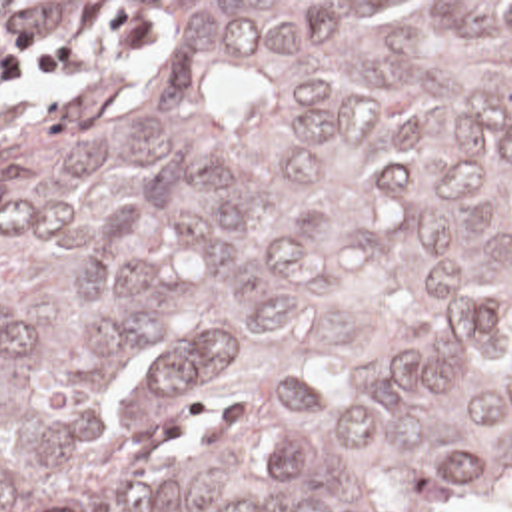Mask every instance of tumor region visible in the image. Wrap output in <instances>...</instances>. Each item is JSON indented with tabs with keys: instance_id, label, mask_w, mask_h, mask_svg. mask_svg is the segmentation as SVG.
<instances>
[{
	"instance_id": "tumor-region-1",
	"label": "tumor region",
	"mask_w": 512,
	"mask_h": 512,
	"mask_svg": "<svg viewBox=\"0 0 512 512\" xmlns=\"http://www.w3.org/2000/svg\"><path fill=\"white\" fill-rule=\"evenodd\" d=\"M158 46L0 144V512H512V2H0Z\"/></svg>"
}]
</instances>
